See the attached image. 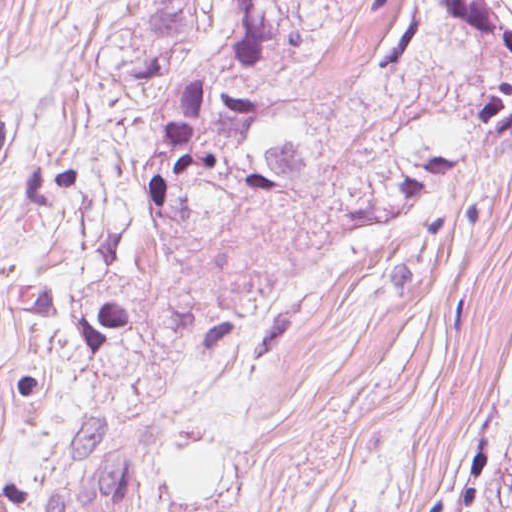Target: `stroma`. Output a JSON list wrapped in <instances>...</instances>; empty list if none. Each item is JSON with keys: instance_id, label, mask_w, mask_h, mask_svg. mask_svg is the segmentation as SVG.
I'll return each mask as SVG.
<instances>
[{"instance_id": "1", "label": "stroma", "mask_w": 512, "mask_h": 512, "mask_svg": "<svg viewBox=\"0 0 512 512\" xmlns=\"http://www.w3.org/2000/svg\"><path fill=\"white\" fill-rule=\"evenodd\" d=\"M409 1L299 74L314 202L199 226L146 280L156 312L88 334L144 246L156 0H0V512H499L512 158L333 240L344 176L411 91L369 90Z\"/></svg>"}]
</instances>
